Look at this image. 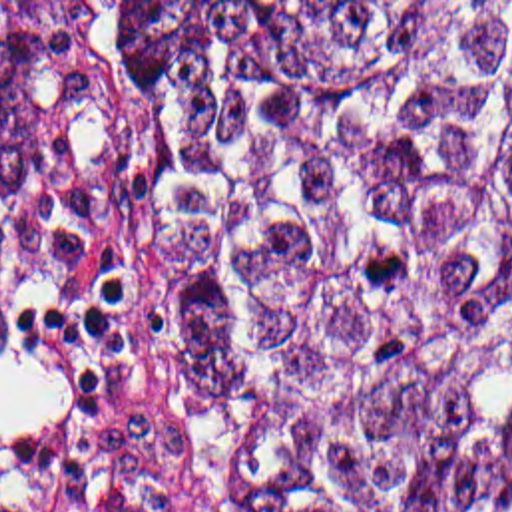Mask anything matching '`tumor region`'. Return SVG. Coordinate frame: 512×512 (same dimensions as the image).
<instances>
[{"label": "tumor region", "mask_w": 512, "mask_h": 512, "mask_svg": "<svg viewBox=\"0 0 512 512\" xmlns=\"http://www.w3.org/2000/svg\"><path fill=\"white\" fill-rule=\"evenodd\" d=\"M156 108L132 341L207 512L512 508V2H110ZM86 12L0 18L48 197Z\"/></svg>", "instance_id": "obj_1"}]
</instances>
